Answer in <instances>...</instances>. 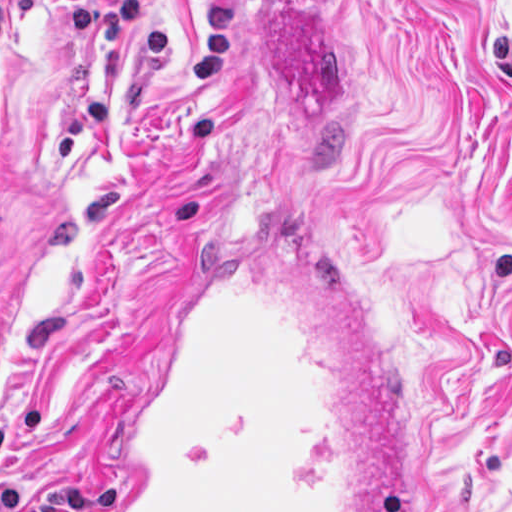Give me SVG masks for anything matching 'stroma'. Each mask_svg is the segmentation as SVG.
<instances>
[{
  "label": "stroma",
  "instance_id": "obj_1",
  "mask_svg": "<svg viewBox=\"0 0 512 512\" xmlns=\"http://www.w3.org/2000/svg\"><path fill=\"white\" fill-rule=\"evenodd\" d=\"M0 489L107 512L200 232L296 185L413 512H512V0H0Z\"/></svg>",
  "mask_w": 512,
  "mask_h": 512
}]
</instances>
